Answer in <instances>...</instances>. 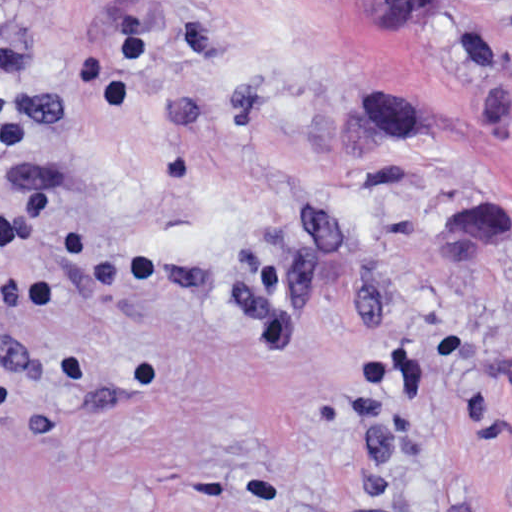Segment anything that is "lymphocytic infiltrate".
I'll return each mask as SVG.
<instances>
[{"label": "lymphocytic infiltrate", "instance_id": "f902f5d3", "mask_svg": "<svg viewBox=\"0 0 512 512\" xmlns=\"http://www.w3.org/2000/svg\"><path fill=\"white\" fill-rule=\"evenodd\" d=\"M105 14L99 37L72 63L89 95L109 116H132L135 97L155 74L149 47V0H99Z\"/></svg>", "mask_w": 512, "mask_h": 512}]
</instances>
